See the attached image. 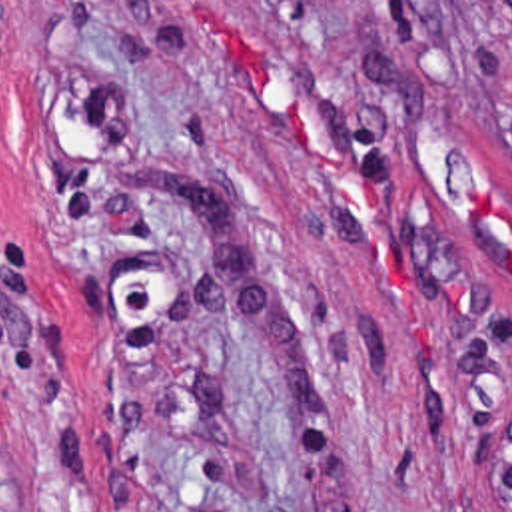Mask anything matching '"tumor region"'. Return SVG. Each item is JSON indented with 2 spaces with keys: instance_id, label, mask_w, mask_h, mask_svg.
I'll use <instances>...</instances> for the list:
<instances>
[{
  "instance_id": "1",
  "label": "tumor region",
  "mask_w": 512,
  "mask_h": 512,
  "mask_svg": "<svg viewBox=\"0 0 512 512\" xmlns=\"http://www.w3.org/2000/svg\"><path fill=\"white\" fill-rule=\"evenodd\" d=\"M502 28H504L508 52L512 56V2H502Z\"/></svg>"
}]
</instances>
